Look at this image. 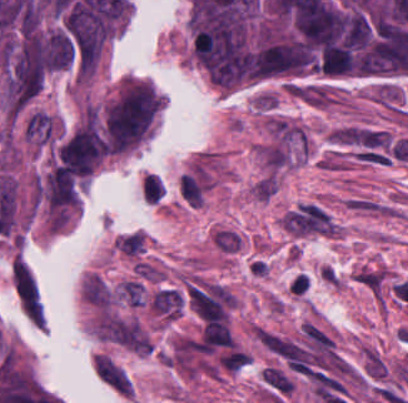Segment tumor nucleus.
Instances as JSON below:
<instances>
[{
	"instance_id": "obj_1",
	"label": "tumor nucleus",
	"mask_w": 408,
	"mask_h": 403,
	"mask_svg": "<svg viewBox=\"0 0 408 403\" xmlns=\"http://www.w3.org/2000/svg\"><path fill=\"white\" fill-rule=\"evenodd\" d=\"M159 103L144 81H130L114 96L101 116L111 154L130 150L149 133Z\"/></svg>"
},
{
	"instance_id": "obj_2",
	"label": "tumor nucleus",
	"mask_w": 408,
	"mask_h": 403,
	"mask_svg": "<svg viewBox=\"0 0 408 403\" xmlns=\"http://www.w3.org/2000/svg\"><path fill=\"white\" fill-rule=\"evenodd\" d=\"M51 127V117L44 112L35 111L25 122V138L38 143H43L48 139Z\"/></svg>"
},
{
	"instance_id": "obj_3",
	"label": "tumor nucleus",
	"mask_w": 408,
	"mask_h": 403,
	"mask_svg": "<svg viewBox=\"0 0 408 403\" xmlns=\"http://www.w3.org/2000/svg\"><path fill=\"white\" fill-rule=\"evenodd\" d=\"M164 187L161 180L154 173H146L140 183V191L148 203L158 201L163 193Z\"/></svg>"
}]
</instances>
